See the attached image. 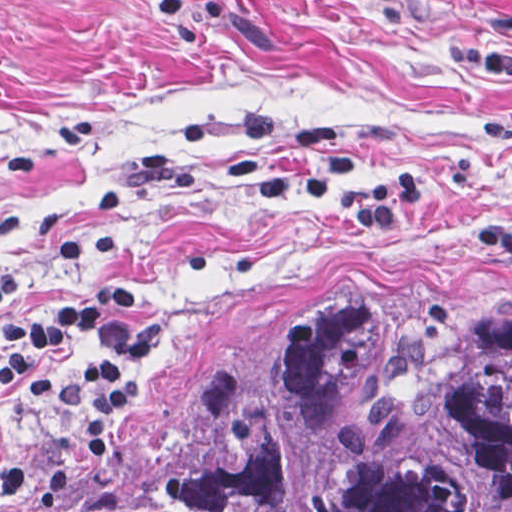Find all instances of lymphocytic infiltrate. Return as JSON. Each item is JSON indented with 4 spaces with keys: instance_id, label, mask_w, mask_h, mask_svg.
<instances>
[{
    "instance_id": "1",
    "label": "lymphocytic infiltrate",
    "mask_w": 512,
    "mask_h": 512,
    "mask_svg": "<svg viewBox=\"0 0 512 512\" xmlns=\"http://www.w3.org/2000/svg\"><path fill=\"white\" fill-rule=\"evenodd\" d=\"M308 157L305 166L265 173L255 192L264 201L297 197L314 206L327 204L333 178L352 173L364 156L379 168L360 186L338 191L342 216L384 240H398L411 226L434 188V174L403 161L387 141L346 148L336 127L313 121L297 129ZM15 224V214L0 211V236ZM117 252L115 228L104 226L67 243L62 263L80 276L59 300L0 327V387H18L34 396L62 400V415L82 452L106 454L104 428L87 418L77 380L60 370L58 352L87 346V377L100 406L108 413L125 409L141 389L142 365L155 353L157 337L142 320L141 299L130 288L101 281ZM15 274L0 271V303L14 295Z\"/></svg>"
}]
</instances>
